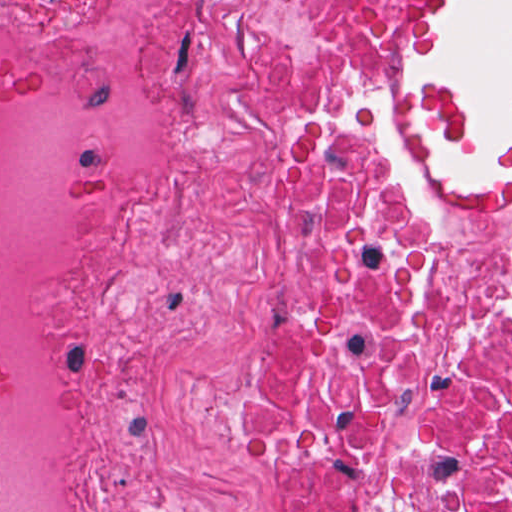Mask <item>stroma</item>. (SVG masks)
<instances>
[{"instance_id": "35a3bbf8", "label": "stroma", "mask_w": 512, "mask_h": 512, "mask_svg": "<svg viewBox=\"0 0 512 512\" xmlns=\"http://www.w3.org/2000/svg\"><path fill=\"white\" fill-rule=\"evenodd\" d=\"M450 0H416L412 65L425 53L431 29ZM412 171L469 210H487L496 200L512 159V139L493 147L497 167L483 181H457L445 171L441 150L461 158L475 143L464 100L425 85L412 72V107L405 135Z\"/></svg>"}]
</instances>
